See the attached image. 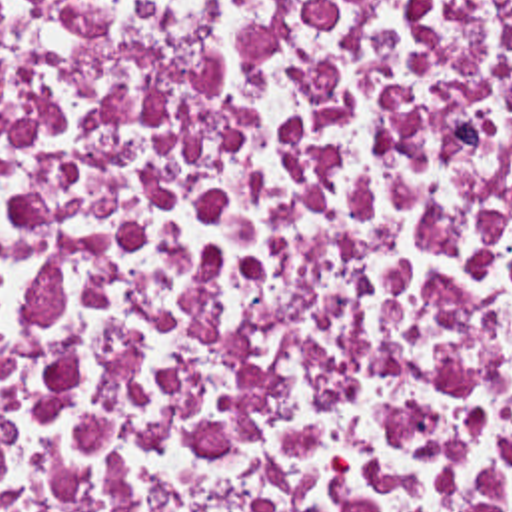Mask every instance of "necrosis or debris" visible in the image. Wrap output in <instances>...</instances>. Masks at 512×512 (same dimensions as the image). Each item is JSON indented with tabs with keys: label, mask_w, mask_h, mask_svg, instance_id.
Instances as JSON below:
<instances>
[{
	"label": "necrosis or debris",
	"mask_w": 512,
	"mask_h": 512,
	"mask_svg": "<svg viewBox=\"0 0 512 512\" xmlns=\"http://www.w3.org/2000/svg\"><path fill=\"white\" fill-rule=\"evenodd\" d=\"M0 512H512V0H0Z\"/></svg>",
	"instance_id": "obj_1"
}]
</instances>
